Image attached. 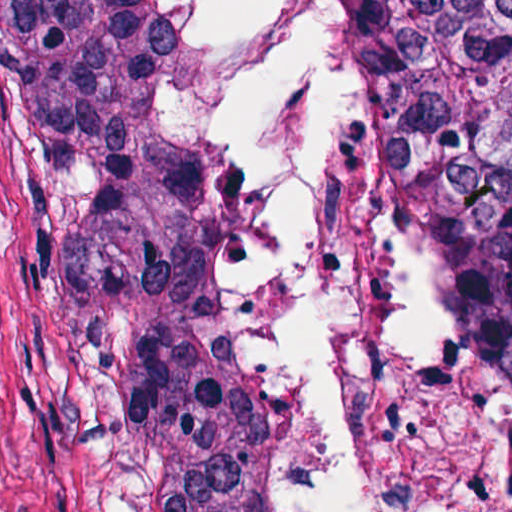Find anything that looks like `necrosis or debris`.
<instances>
[{"label": "necrosis or debris", "instance_id": "obj_1", "mask_svg": "<svg viewBox=\"0 0 512 512\" xmlns=\"http://www.w3.org/2000/svg\"><path fill=\"white\" fill-rule=\"evenodd\" d=\"M180 8L142 103L229 165L266 512H512V395L380 169L343 1Z\"/></svg>", "mask_w": 512, "mask_h": 512}]
</instances>
